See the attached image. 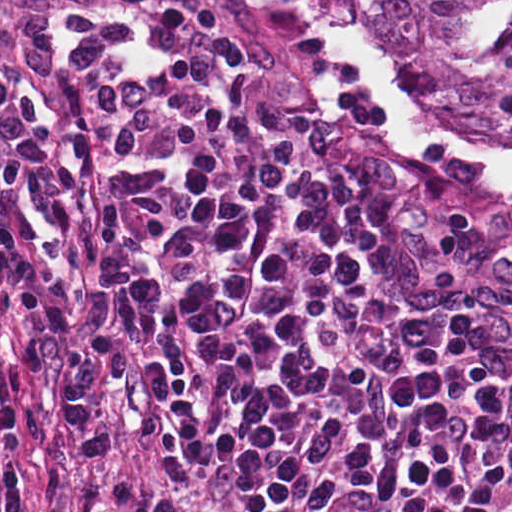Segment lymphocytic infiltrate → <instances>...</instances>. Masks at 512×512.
<instances>
[{"instance_id":"1","label":"lymphocytic infiltrate","mask_w":512,"mask_h":512,"mask_svg":"<svg viewBox=\"0 0 512 512\" xmlns=\"http://www.w3.org/2000/svg\"><path fill=\"white\" fill-rule=\"evenodd\" d=\"M21 324L17 347L20 369L28 378L47 371L46 345L61 346L68 378V399L74 444L80 454L95 458L107 448V436L91 392L89 351L82 332L76 331L47 298L36 279L14 263L0 259V452H8L17 434L11 383L4 352L5 316ZM41 512H68L47 500ZM124 512H194L183 502L147 494L131 502Z\"/></svg>"}]
</instances>
